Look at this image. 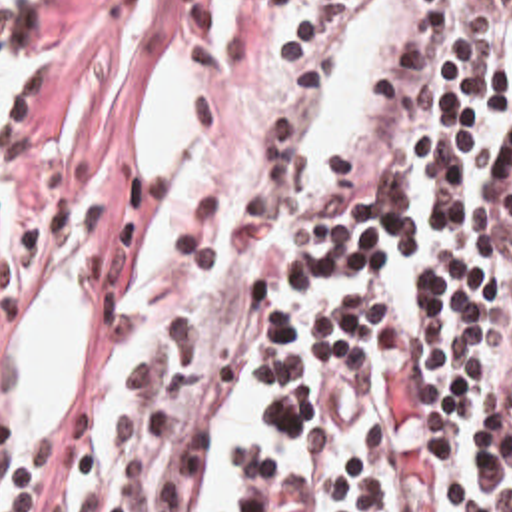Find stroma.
<instances>
[{
	"label": "stroma",
	"instance_id": "1",
	"mask_svg": "<svg viewBox=\"0 0 512 512\" xmlns=\"http://www.w3.org/2000/svg\"><path fill=\"white\" fill-rule=\"evenodd\" d=\"M213 0H48L22 167L0 185V446L18 430L16 342L44 287L76 267L88 299L140 175L154 77L209 53Z\"/></svg>",
	"mask_w": 512,
	"mask_h": 512
}]
</instances>
